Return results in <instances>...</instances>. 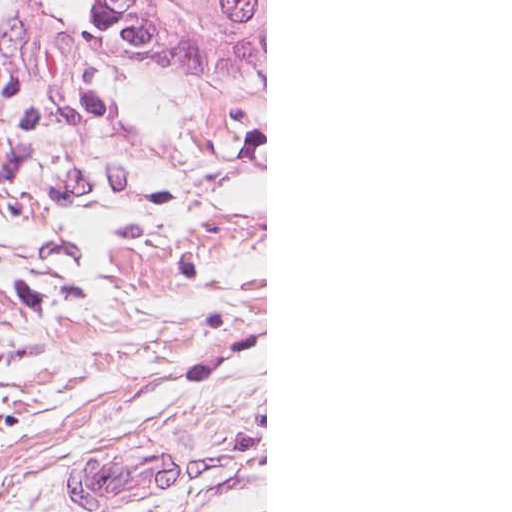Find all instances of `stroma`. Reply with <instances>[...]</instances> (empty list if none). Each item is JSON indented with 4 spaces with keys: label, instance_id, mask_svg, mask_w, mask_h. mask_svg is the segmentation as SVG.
<instances>
[{
    "label": "stroma",
    "instance_id": "1",
    "mask_svg": "<svg viewBox=\"0 0 512 512\" xmlns=\"http://www.w3.org/2000/svg\"><path fill=\"white\" fill-rule=\"evenodd\" d=\"M0 512H223L0 464Z\"/></svg>",
    "mask_w": 512,
    "mask_h": 512
}]
</instances>
